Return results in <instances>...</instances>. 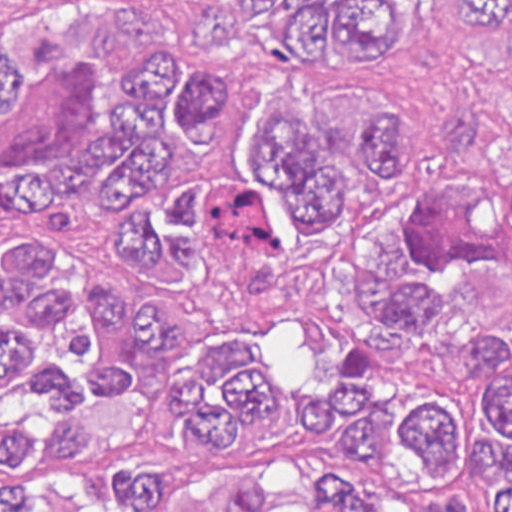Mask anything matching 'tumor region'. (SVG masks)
<instances>
[{
    "mask_svg": "<svg viewBox=\"0 0 512 512\" xmlns=\"http://www.w3.org/2000/svg\"><path fill=\"white\" fill-rule=\"evenodd\" d=\"M54 4L1 27L0 512H512V327H488L422 237L479 217L512 249V160L489 198L377 205L413 175V114L375 69L425 0H234L317 92L252 117L247 57L206 0ZM512 68V0H455ZM327 248L349 361L310 445L256 477H186L147 449L257 460L298 397L252 335L298 314Z\"/></svg>",
    "mask_w": 512,
    "mask_h": 512,
    "instance_id": "obj_1",
    "label": "tumor region"
}]
</instances>
